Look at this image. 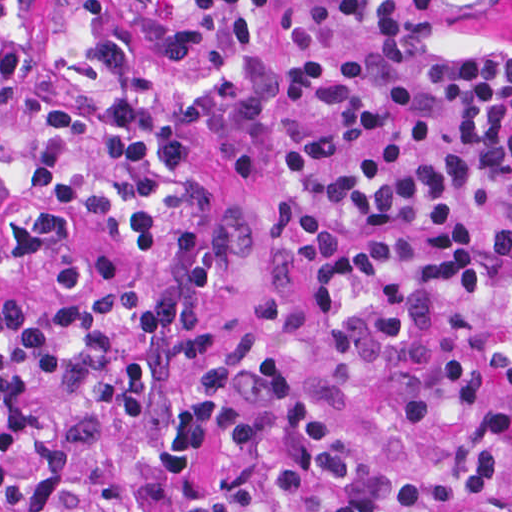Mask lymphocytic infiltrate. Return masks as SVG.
Segmentation results:
<instances>
[{
	"label": "lymphocytic infiltrate",
	"instance_id": "1",
	"mask_svg": "<svg viewBox=\"0 0 512 512\" xmlns=\"http://www.w3.org/2000/svg\"><path fill=\"white\" fill-rule=\"evenodd\" d=\"M0 0V512H512V45L442 0Z\"/></svg>",
	"mask_w": 512,
	"mask_h": 512
}]
</instances>
